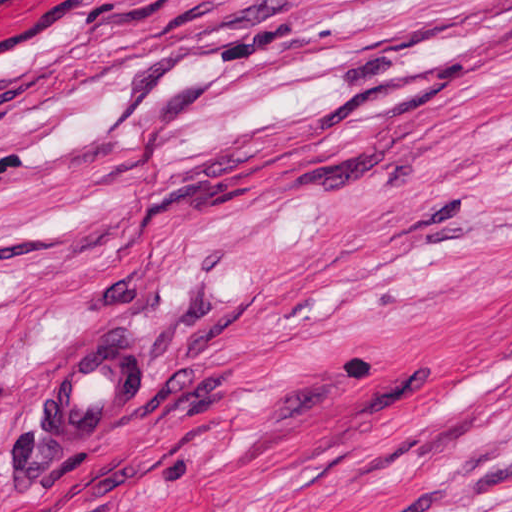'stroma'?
I'll return each mask as SVG.
<instances>
[{
  "mask_svg": "<svg viewBox=\"0 0 512 512\" xmlns=\"http://www.w3.org/2000/svg\"><path fill=\"white\" fill-rule=\"evenodd\" d=\"M0 512H512V0H0Z\"/></svg>",
  "mask_w": 512,
  "mask_h": 512,
  "instance_id": "stroma-1",
  "label": "stroma"
}]
</instances>
